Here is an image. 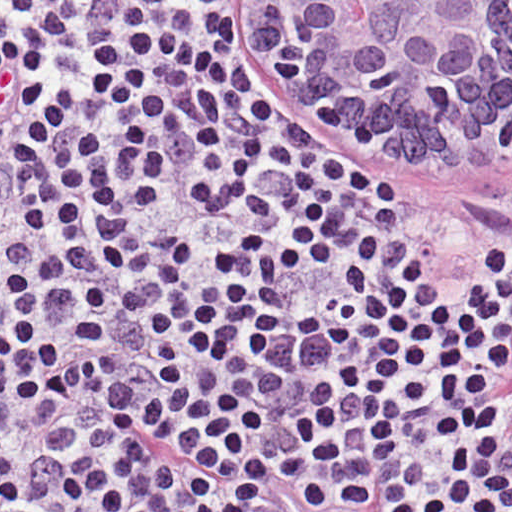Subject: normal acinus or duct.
I'll return each mask as SVG.
<instances>
[{"label": "normal acinus or duct", "mask_w": 512, "mask_h": 512, "mask_svg": "<svg viewBox=\"0 0 512 512\" xmlns=\"http://www.w3.org/2000/svg\"><path fill=\"white\" fill-rule=\"evenodd\" d=\"M305 108L401 154L403 175L471 178L512 154V1H271Z\"/></svg>", "instance_id": "1"}]
</instances>
